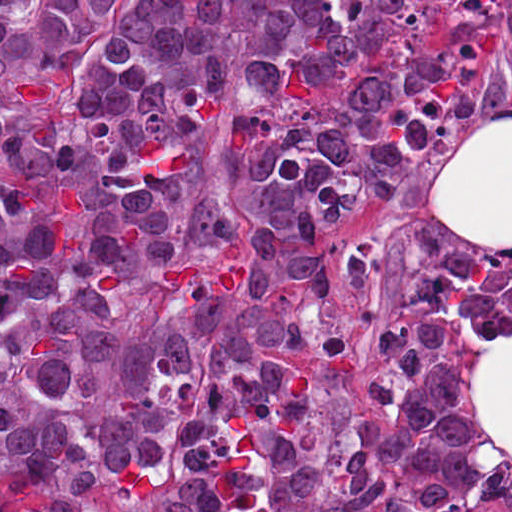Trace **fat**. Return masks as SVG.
I'll return each instance as SVG.
<instances>
[{"mask_svg":"<svg viewBox=\"0 0 512 512\" xmlns=\"http://www.w3.org/2000/svg\"><path fill=\"white\" fill-rule=\"evenodd\" d=\"M433 205L473 250H512V114L485 112L446 157ZM473 395L485 437L470 460L482 469L512 461V337L473 362Z\"/></svg>","mask_w":512,"mask_h":512,"instance_id":"fat-1","label":"fat"}]
</instances>
